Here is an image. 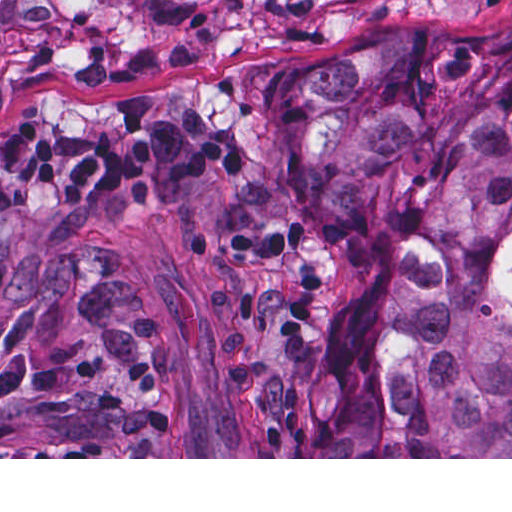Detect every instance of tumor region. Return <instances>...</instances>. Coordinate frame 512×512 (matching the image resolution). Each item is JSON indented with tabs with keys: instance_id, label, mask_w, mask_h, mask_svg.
<instances>
[{
	"instance_id": "e687c5a6",
	"label": "tumor region",
	"mask_w": 512,
	"mask_h": 512,
	"mask_svg": "<svg viewBox=\"0 0 512 512\" xmlns=\"http://www.w3.org/2000/svg\"><path fill=\"white\" fill-rule=\"evenodd\" d=\"M222 260L218 381L265 457H512V19L377 37L238 140L194 95L0 117V457H172L146 308L94 232Z\"/></svg>"
}]
</instances>
